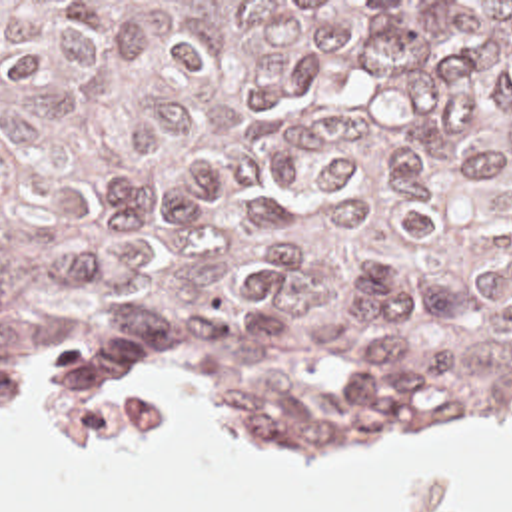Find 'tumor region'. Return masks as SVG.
<instances>
[{"instance_id":"obj_1","label":"tumor region","mask_w":512,"mask_h":512,"mask_svg":"<svg viewBox=\"0 0 512 512\" xmlns=\"http://www.w3.org/2000/svg\"><path fill=\"white\" fill-rule=\"evenodd\" d=\"M204 321L275 425L512 417V2H0V403Z\"/></svg>"}]
</instances>
